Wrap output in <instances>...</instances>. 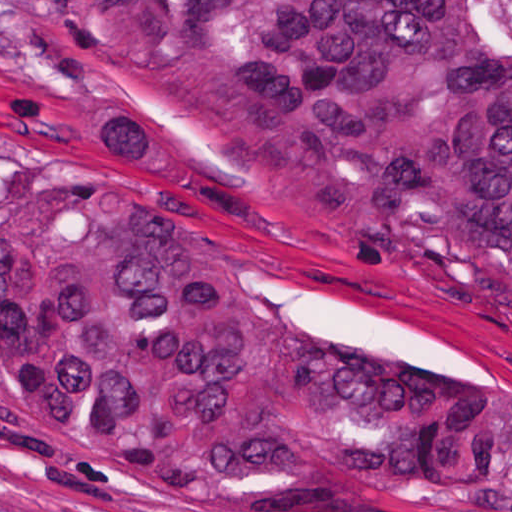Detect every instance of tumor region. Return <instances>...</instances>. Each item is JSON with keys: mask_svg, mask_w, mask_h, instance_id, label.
<instances>
[{"mask_svg": "<svg viewBox=\"0 0 512 512\" xmlns=\"http://www.w3.org/2000/svg\"><path fill=\"white\" fill-rule=\"evenodd\" d=\"M223 201L512 337V0H66ZM1 395L68 463L167 498H453L512 376L318 333L144 196L1 223Z\"/></svg>", "mask_w": 512, "mask_h": 512, "instance_id": "obj_1", "label": "tumor region"}]
</instances>
